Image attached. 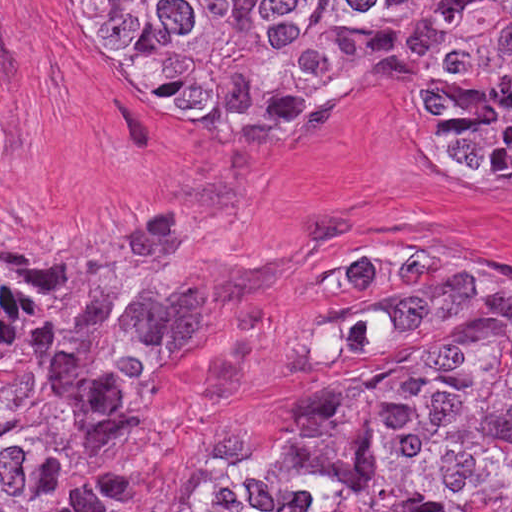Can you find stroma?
Wrapping results in <instances>:
<instances>
[{
  "instance_id": "obj_1",
  "label": "stroma",
  "mask_w": 512,
  "mask_h": 512,
  "mask_svg": "<svg viewBox=\"0 0 512 512\" xmlns=\"http://www.w3.org/2000/svg\"><path fill=\"white\" fill-rule=\"evenodd\" d=\"M404 59L233 145L167 126L68 46L54 0H0V272L45 284L167 217L219 213L213 281L127 355L131 445L101 512H192L236 446L240 388L344 263L403 240L463 250L512 282V177L426 161Z\"/></svg>"
}]
</instances>
